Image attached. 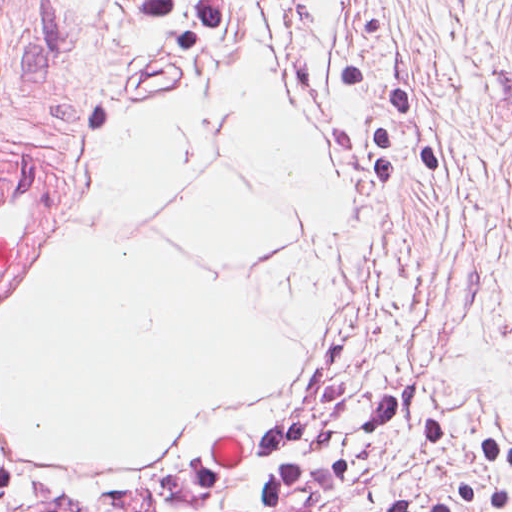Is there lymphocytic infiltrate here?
Masks as SVG:
<instances>
[{
  "label": "lymphocytic infiltrate",
  "instance_id": "1",
  "mask_svg": "<svg viewBox=\"0 0 512 512\" xmlns=\"http://www.w3.org/2000/svg\"><path fill=\"white\" fill-rule=\"evenodd\" d=\"M360 365L277 430L232 455L88 490L0 481V512H339L358 468L333 422L346 381ZM365 387L364 428L374 441H389L422 410L426 453L444 463L458 460L464 472L463 490L416 500L399 512H512V444L473 423L392 400L366 379Z\"/></svg>",
  "mask_w": 512,
  "mask_h": 512
}]
</instances>
